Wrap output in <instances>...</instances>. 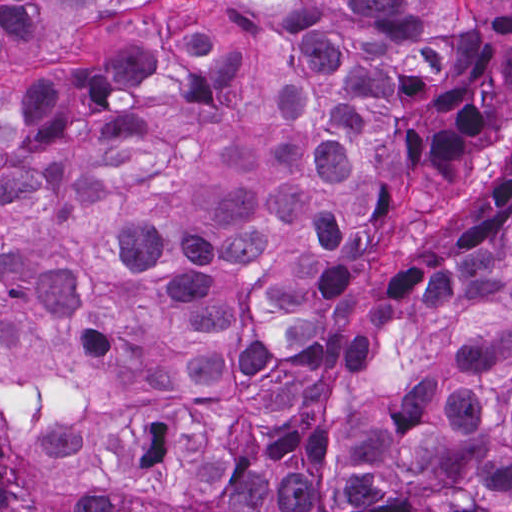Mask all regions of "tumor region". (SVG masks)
<instances>
[{
    "instance_id": "tumor-region-1",
    "label": "tumor region",
    "mask_w": 512,
    "mask_h": 512,
    "mask_svg": "<svg viewBox=\"0 0 512 512\" xmlns=\"http://www.w3.org/2000/svg\"><path fill=\"white\" fill-rule=\"evenodd\" d=\"M0 512H512V1H148L0 93Z\"/></svg>"
}]
</instances>
